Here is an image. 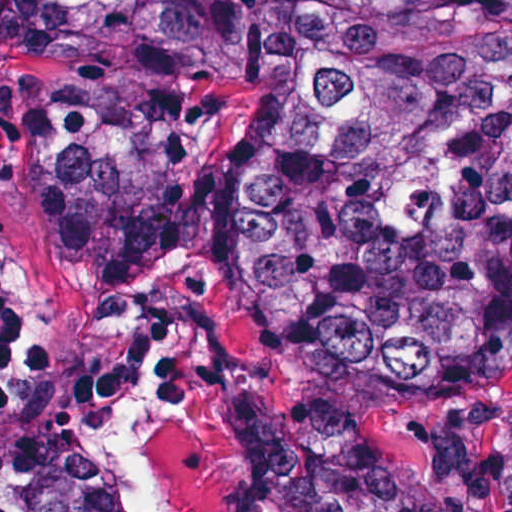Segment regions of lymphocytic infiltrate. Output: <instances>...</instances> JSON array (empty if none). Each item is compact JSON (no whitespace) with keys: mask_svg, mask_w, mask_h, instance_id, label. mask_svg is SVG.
<instances>
[{"mask_svg":"<svg viewBox=\"0 0 512 512\" xmlns=\"http://www.w3.org/2000/svg\"><path fill=\"white\" fill-rule=\"evenodd\" d=\"M14 303L0 260V360L12 341Z\"/></svg>","mask_w":512,"mask_h":512,"instance_id":"1","label":"lymphocytic infiltrate"}]
</instances>
